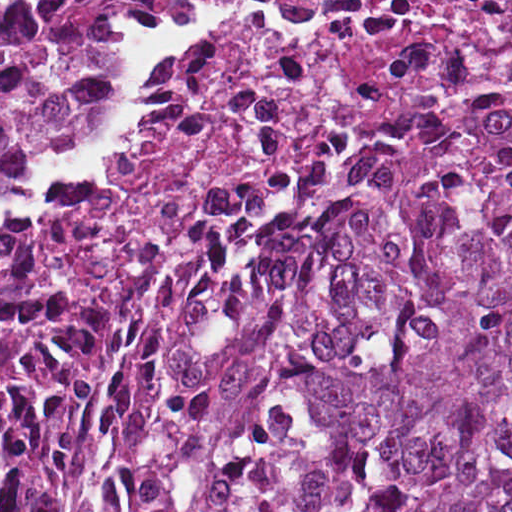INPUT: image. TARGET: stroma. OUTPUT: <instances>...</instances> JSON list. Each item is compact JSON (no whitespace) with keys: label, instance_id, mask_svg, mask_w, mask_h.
<instances>
[{"label":"stroma","instance_id":"1","mask_svg":"<svg viewBox=\"0 0 512 512\" xmlns=\"http://www.w3.org/2000/svg\"><path fill=\"white\" fill-rule=\"evenodd\" d=\"M187 3L188 0H164L151 6L121 8L123 65L106 128L92 141L78 146L61 159L26 169L3 190H0V232H13L28 237L29 259L37 283L49 295L66 304L85 320L101 318L112 301H82L57 285L49 269L46 254L38 241V222L43 203L46 195L58 183L97 160L116 135L125 110L135 94L133 68L135 35L176 17L184 10ZM507 85H512V72L487 73L445 81L417 91L407 102L365 117L317 154L275 171L268 182L252 194L240 213L228 225L195 243L171 248L144 259L135 266L125 284L141 268L183 267L225 243L297 175L322 163L348 140L362 135L372 124L394 111L410 103L428 101L441 95L479 93Z\"/></svg>","mask_w":512,"mask_h":512}]
</instances>
